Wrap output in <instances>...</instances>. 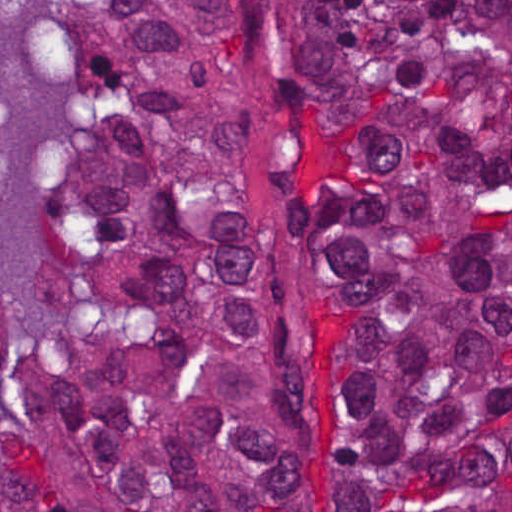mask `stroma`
Masks as SVG:
<instances>
[{"instance_id": "1", "label": "stroma", "mask_w": 512, "mask_h": 512, "mask_svg": "<svg viewBox=\"0 0 512 512\" xmlns=\"http://www.w3.org/2000/svg\"><path fill=\"white\" fill-rule=\"evenodd\" d=\"M5 1V100L20 153V193L0 204V280L9 322L27 336L49 257V209L80 137L77 77L46 17V1L512 0H0Z\"/></svg>"}]
</instances>
